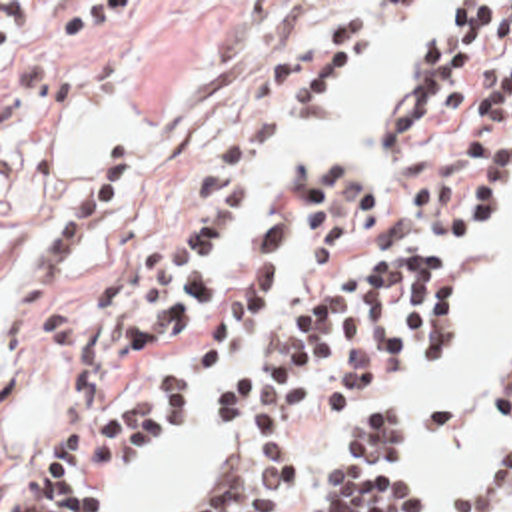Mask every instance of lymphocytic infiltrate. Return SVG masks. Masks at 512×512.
Masks as SVG:
<instances>
[{
	"instance_id": "f902f5d3",
	"label": "lymphocytic infiltrate",
	"mask_w": 512,
	"mask_h": 512,
	"mask_svg": "<svg viewBox=\"0 0 512 512\" xmlns=\"http://www.w3.org/2000/svg\"><path fill=\"white\" fill-rule=\"evenodd\" d=\"M325 20L270 54L246 84L186 204L142 238L90 302L52 306L88 242L124 204L130 144L110 146L70 194L32 252L8 304V335L36 321L42 341L76 351V393H94L200 312L218 274L222 236L244 216L242 182L284 116L319 98L343 68L403 32L425 2H319ZM401 24L397 26V22ZM397 30L389 34L393 28ZM505 52L461 128L467 152L419 162L407 200L437 226L419 238L385 236L387 186L377 164L329 144L297 162L307 302L276 327L258 363L238 377L286 300V222L274 220L200 339L144 397L110 421L48 439L18 512H90L166 431L212 393L214 417L238 431L214 451L170 512H286L301 469V415L331 417L377 391L449 361L459 341V278L401 244L477 242L512 186V2H449L419 32L409 92L383 110V146L461 122L477 70ZM489 423L512 429V385H481ZM417 435L413 409L383 401L343 427L339 457L311 483L315 512H425V491L403 467ZM453 512H512V445L455 493Z\"/></svg>"
}]
</instances>
